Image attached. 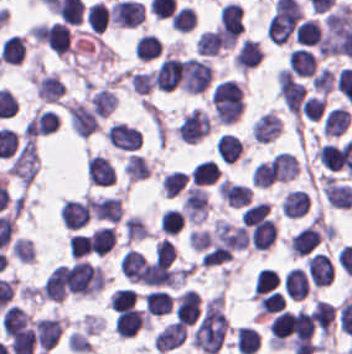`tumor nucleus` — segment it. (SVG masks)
Wrapping results in <instances>:
<instances>
[{
    "label": "tumor nucleus",
    "mask_w": 352,
    "mask_h": 354,
    "mask_svg": "<svg viewBox=\"0 0 352 354\" xmlns=\"http://www.w3.org/2000/svg\"><path fill=\"white\" fill-rule=\"evenodd\" d=\"M228 328L227 315L221 295L207 300L194 327L191 342L204 353H212L222 344Z\"/></svg>",
    "instance_id": "1"
}]
</instances>
